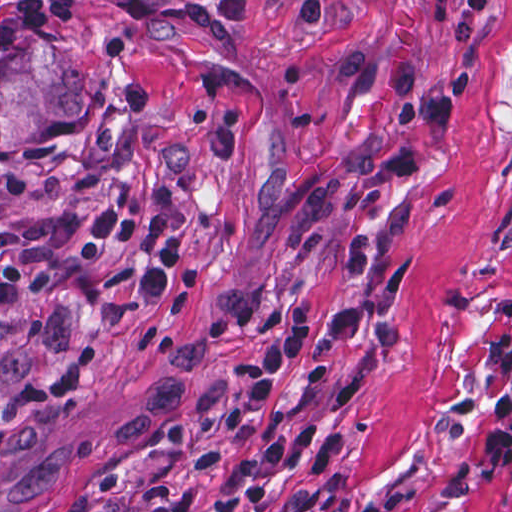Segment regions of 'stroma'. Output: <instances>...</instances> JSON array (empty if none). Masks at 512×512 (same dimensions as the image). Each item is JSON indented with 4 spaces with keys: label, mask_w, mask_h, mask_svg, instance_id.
<instances>
[{
    "label": "stroma",
    "mask_w": 512,
    "mask_h": 512,
    "mask_svg": "<svg viewBox=\"0 0 512 512\" xmlns=\"http://www.w3.org/2000/svg\"><path fill=\"white\" fill-rule=\"evenodd\" d=\"M14 0H0V14ZM72 0L42 27L91 83L86 115L0 152V231L118 193L181 243L166 303L137 256L51 252L37 291L0 305V406L54 358L86 379L0 442V512H64L118 462L147 473L206 440L265 329L321 309L295 374L239 464L195 512H272L313 490L360 512H512V468L481 436L512 383V0ZM416 59L454 115L428 163L382 167L400 108L351 96L337 55Z\"/></svg>",
    "instance_id": "1"
}]
</instances>
